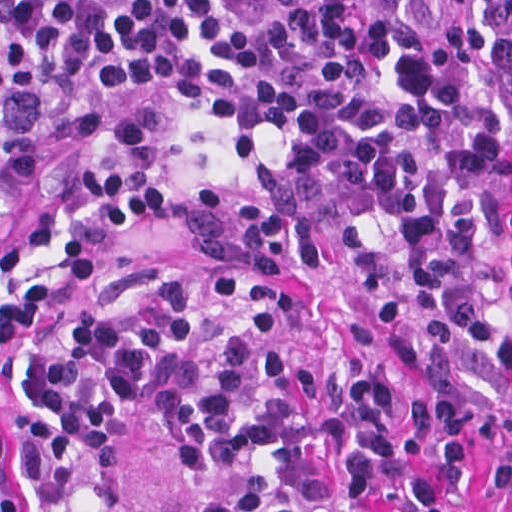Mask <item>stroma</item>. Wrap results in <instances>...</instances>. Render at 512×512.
Wrapping results in <instances>:
<instances>
[{"label": "stroma", "mask_w": 512, "mask_h": 512, "mask_svg": "<svg viewBox=\"0 0 512 512\" xmlns=\"http://www.w3.org/2000/svg\"><path fill=\"white\" fill-rule=\"evenodd\" d=\"M306 135L201 97H98L60 130L11 149L1 174L0 0V512L10 491L1 444L20 418L22 342L152 281H189L216 318L330 350L357 374L381 368L409 388L430 385L341 289L222 269L183 221L188 197L245 181ZM180 488L140 424L110 492L66 512H133ZM491 494L492 457L478 438L468 512H490Z\"/></svg>", "instance_id": "35a3bbf8"}]
</instances>
